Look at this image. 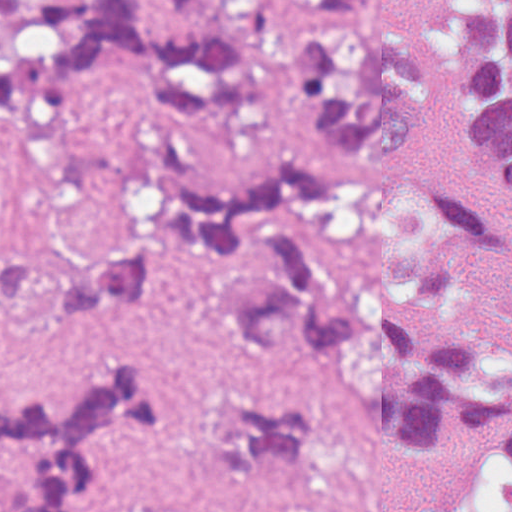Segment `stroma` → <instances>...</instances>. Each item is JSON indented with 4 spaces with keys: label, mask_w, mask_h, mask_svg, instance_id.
Instances as JSON below:
<instances>
[{
    "label": "stroma",
    "mask_w": 512,
    "mask_h": 512,
    "mask_svg": "<svg viewBox=\"0 0 512 512\" xmlns=\"http://www.w3.org/2000/svg\"><path fill=\"white\" fill-rule=\"evenodd\" d=\"M453 0H381L385 21L417 43ZM293 90L215 114H163L125 94L99 98L64 126L0 128V228L34 262H84L119 240L131 197L168 170H238L290 131ZM148 362L178 383L187 410L112 447L106 486L123 502L220 499L222 430L254 407L325 404L331 428L296 512H446L470 444L446 434L402 441L383 430L330 348L312 337L278 361H249L208 308L203 262L180 251L160 284L100 316L28 320L0 311V376L57 397L88 369ZM1 490V475H0Z\"/></svg>",
    "instance_id": "stroma-1"
}]
</instances>
